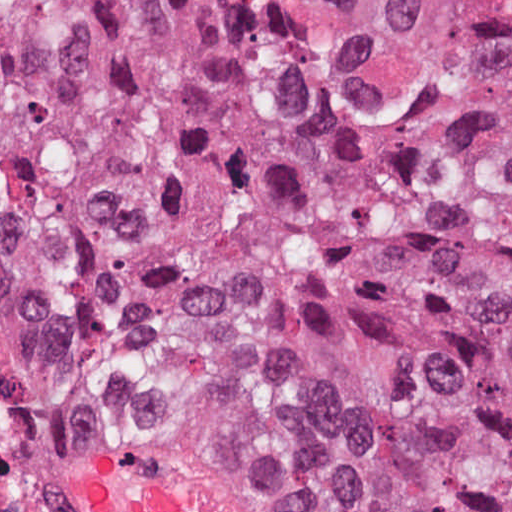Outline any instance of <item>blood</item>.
Instances as JSON below:
<instances>
[{
  "label": "blood",
  "instance_id": "blood-1",
  "mask_svg": "<svg viewBox=\"0 0 512 512\" xmlns=\"http://www.w3.org/2000/svg\"><path fill=\"white\" fill-rule=\"evenodd\" d=\"M83 512H234L93 455L79 486Z\"/></svg>",
  "mask_w": 512,
  "mask_h": 512
}]
</instances>
